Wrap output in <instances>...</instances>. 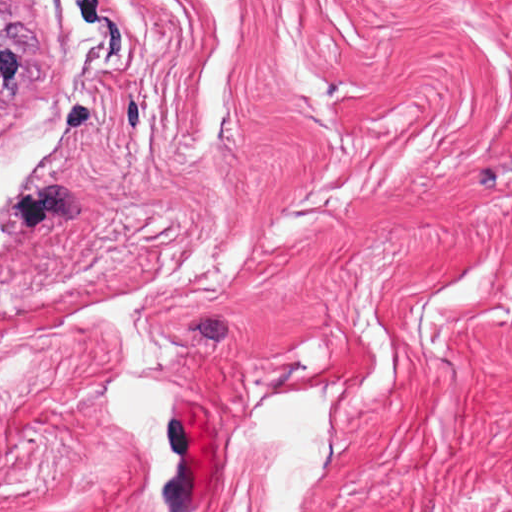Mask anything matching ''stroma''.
Listing matches in <instances>:
<instances>
[{
	"instance_id": "stroma-1",
	"label": "stroma",
	"mask_w": 512,
	"mask_h": 512,
	"mask_svg": "<svg viewBox=\"0 0 512 512\" xmlns=\"http://www.w3.org/2000/svg\"><path fill=\"white\" fill-rule=\"evenodd\" d=\"M5 1L0 154L64 133L0 210V450L145 465L130 371L263 477L247 403L323 381L315 483L512 503V0Z\"/></svg>"
}]
</instances>
